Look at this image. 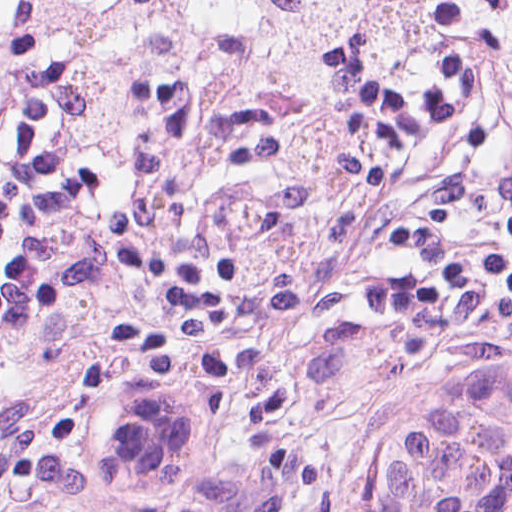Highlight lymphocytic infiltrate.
<instances>
[{
  "mask_svg": "<svg viewBox=\"0 0 512 512\" xmlns=\"http://www.w3.org/2000/svg\"><path fill=\"white\" fill-rule=\"evenodd\" d=\"M48 201V1L0 77V277ZM512 373V61L238 395L296 444L366 436L446 375ZM497 512H512V471Z\"/></svg>",
  "mask_w": 512,
  "mask_h": 512,
  "instance_id": "f902f5d3",
  "label": "lymphocytic infiltrate"
}]
</instances>
